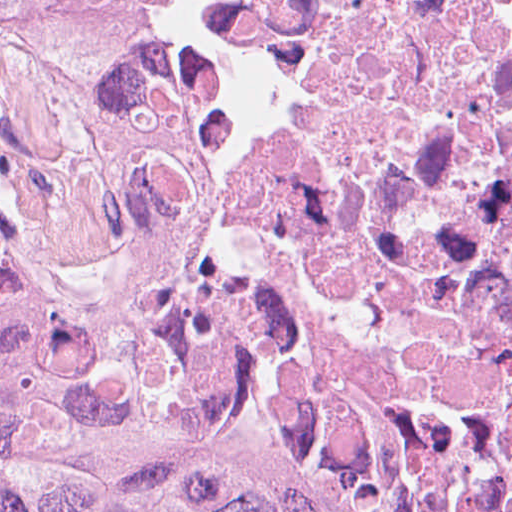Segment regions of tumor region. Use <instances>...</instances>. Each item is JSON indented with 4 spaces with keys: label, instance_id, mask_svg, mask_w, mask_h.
<instances>
[{
    "label": "tumor region",
    "instance_id": "obj_1",
    "mask_svg": "<svg viewBox=\"0 0 512 512\" xmlns=\"http://www.w3.org/2000/svg\"><path fill=\"white\" fill-rule=\"evenodd\" d=\"M0 512H512L379 486L290 449L242 356L205 326L87 320L0 230Z\"/></svg>",
    "mask_w": 512,
    "mask_h": 512
}]
</instances>
